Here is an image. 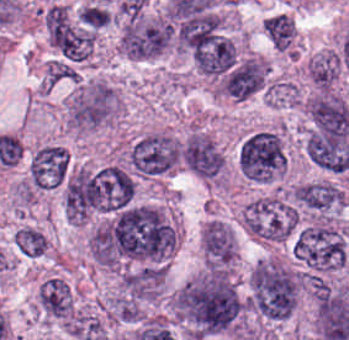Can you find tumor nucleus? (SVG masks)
<instances>
[{
  "mask_svg": "<svg viewBox=\"0 0 349 340\" xmlns=\"http://www.w3.org/2000/svg\"><path fill=\"white\" fill-rule=\"evenodd\" d=\"M170 312L189 339L239 335L243 300L232 274L203 268L169 295Z\"/></svg>",
  "mask_w": 349,
  "mask_h": 340,
  "instance_id": "tumor-nucleus-1",
  "label": "tumor nucleus"
},
{
  "mask_svg": "<svg viewBox=\"0 0 349 340\" xmlns=\"http://www.w3.org/2000/svg\"><path fill=\"white\" fill-rule=\"evenodd\" d=\"M301 272L287 259L261 257L247 277L245 302L266 321H280L297 306Z\"/></svg>",
  "mask_w": 349,
  "mask_h": 340,
  "instance_id": "tumor-nucleus-2",
  "label": "tumor nucleus"
},
{
  "mask_svg": "<svg viewBox=\"0 0 349 340\" xmlns=\"http://www.w3.org/2000/svg\"><path fill=\"white\" fill-rule=\"evenodd\" d=\"M122 109L118 89L101 76L74 81L64 99L67 128L84 133L112 126Z\"/></svg>",
  "mask_w": 349,
  "mask_h": 340,
  "instance_id": "tumor-nucleus-3",
  "label": "tumor nucleus"
},
{
  "mask_svg": "<svg viewBox=\"0 0 349 340\" xmlns=\"http://www.w3.org/2000/svg\"><path fill=\"white\" fill-rule=\"evenodd\" d=\"M348 242L349 227L344 221L319 220L297 227L290 248L303 268L325 273L345 264Z\"/></svg>",
  "mask_w": 349,
  "mask_h": 340,
  "instance_id": "tumor-nucleus-4",
  "label": "tumor nucleus"
},
{
  "mask_svg": "<svg viewBox=\"0 0 349 340\" xmlns=\"http://www.w3.org/2000/svg\"><path fill=\"white\" fill-rule=\"evenodd\" d=\"M118 53L131 59L155 57L171 48V27L160 13L138 11L117 18Z\"/></svg>",
  "mask_w": 349,
  "mask_h": 340,
  "instance_id": "tumor-nucleus-5",
  "label": "tumor nucleus"
},
{
  "mask_svg": "<svg viewBox=\"0 0 349 340\" xmlns=\"http://www.w3.org/2000/svg\"><path fill=\"white\" fill-rule=\"evenodd\" d=\"M297 213L282 195H257L244 205L238 223L244 232L260 242L283 243L296 227Z\"/></svg>",
  "mask_w": 349,
  "mask_h": 340,
  "instance_id": "tumor-nucleus-6",
  "label": "tumor nucleus"
},
{
  "mask_svg": "<svg viewBox=\"0 0 349 340\" xmlns=\"http://www.w3.org/2000/svg\"><path fill=\"white\" fill-rule=\"evenodd\" d=\"M285 159L282 134L275 127L256 129L242 137L237 145L239 172L258 183L276 179L283 172Z\"/></svg>",
  "mask_w": 349,
  "mask_h": 340,
  "instance_id": "tumor-nucleus-7",
  "label": "tumor nucleus"
},
{
  "mask_svg": "<svg viewBox=\"0 0 349 340\" xmlns=\"http://www.w3.org/2000/svg\"><path fill=\"white\" fill-rule=\"evenodd\" d=\"M48 45L65 61L85 63L91 56V27L60 2L43 9Z\"/></svg>",
  "mask_w": 349,
  "mask_h": 340,
  "instance_id": "tumor-nucleus-8",
  "label": "tumor nucleus"
},
{
  "mask_svg": "<svg viewBox=\"0 0 349 340\" xmlns=\"http://www.w3.org/2000/svg\"><path fill=\"white\" fill-rule=\"evenodd\" d=\"M125 159L133 175L141 178L165 175L179 164V139L170 131H149L132 141Z\"/></svg>",
  "mask_w": 349,
  "mask_h": 340,
  "instance_id": "tumor-nucleus-9",
  "label": "tumor nucleus"
},
{
  "mask_svg": "<svg viewBox=\"0 0 349 340\" xmlns=\"http://www.w3.org/2000/svg\"><path fill=\"white\" fill-rule=\"evenodd\" d=\"M179 158L198 178L208 183L222 184L224 155L208 132L189 131L179 143Z\"/></svg>",
  "mask_w": 349,
  "mask_h": 340,
  "instance_id": "tumor-nucleus-10",
  "label": "tumor nucleus"
},
{
  "mask_svg": "<svg viewBox=\"0 0 349 340\" xmlns=\"http://www.w3.org/2000/svg\"><path fill=\"white\" fill-rule=\"evenodd\" d=\"M289 199L293 207L313 220H333L345 200L346 193L324 179L292 185Z\"/></svg>",
  "mask_w": 349,
  "mask_h": 340,
  "instance_id": "tumor-nucleus-11",
  "label": "tumor nucleus"
},
{
  "mask_svg": "<svg viewBox=\"0 0 349 340\" xmlns=\"http://www.w3.org/2000/svg\"><path fill=\"white\" fill-rule=\"evenodd\" d=\"M68 166V152L58 142L34 146L27 155L28 182L32 190L58 188Z\"/></svg>",
  "mask_w": 349,
  "mask_h": 340,
  "instance_id": "tumor-nucleus-12",
  "label": "tumor nucleus"
},
{
  "mask_svg": "<svg viewBox=\"0 0 349 340\" xmlns=\"http://www.w3.org/2000/svg\"><path fill=\"white\" fill-rule=\"evenodd\" d=\"M202 267L208 269H231L236 257V242L232 226L208 219L200 233Z\"/></svg>",
  "mask_w": 349,
  "mask_h": 340,
  "instance_id": "tumor-nucleus-13",
  "label": "tumor nucleus"
},
{
  "mask_svg": "<svg viewBox=\"0 0 349 340\" xmlns=\"http://www.w3.org/2000/svg\"><path fill=\"white\" fill-rule=\"evenodd\" d=\"M75 310V302L68 280L50 275L36 290L33 313L47 321L66 324Z\"/></svg>",
  "mask_w": 349,
  "mask_h": 340,
  "instance_id": "tumor-nucleus-14",
  "label": "tumor nucleus"
},
{
  "mask_svg": "<svg viewBox=\"0 0 349 340\" xmlns=\"http://www.w3.org/2000/svg\"><path fill=\"white\" fill-rule=\"evenodd\" d=\"M263 35L278 51H291L297 43L296 23L286 13H273L260 24Z\"/></svg>",
  "mask_w": 349,
  "mask_h": 340,
  "instance_id": "tumor-nucleus-15",
  "label": "tumor nucleus"
},
{
  "mask_svg": "<svg viewBox=\"0 0 349 340\" xmlns=\"http://www.w3.org/2000/svg\"><path fill=\"white\" fill-rule=\"evenodd\" d=\"M13 245L26 257H39L48 250V240L44 233L36 226L23 224L13 235Z\"/></svg>",
  "mask_w": 349,
  "mask_h": 340,
  "instance_id": "tumor-nucleus-16",
  "label": "tumor nucleus"
}]
</instances>
